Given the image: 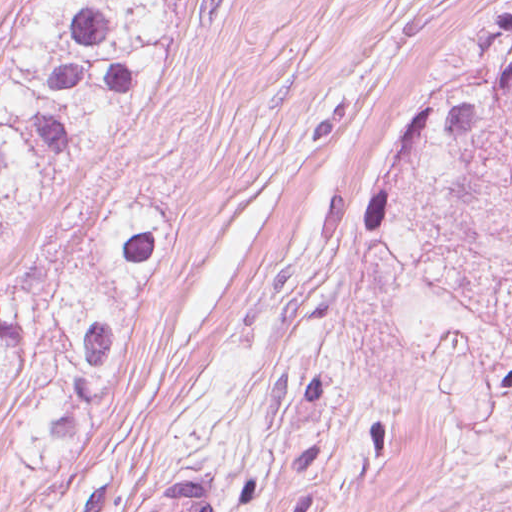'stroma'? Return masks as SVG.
Masks as SVG:
<instances>
[{
  "mask_svg": "<svg viewBox=\"0 0 512 512\" xmlns=\"http://www.w3.org/2000/svg\"><path fill=\"white\" fill-rule=\"evenodd\" d=\"M28 0H0V49ZM436 82L187 2L148 105L0 248L103 192L179 209L105 425L0 512H512V116L459 128L368 233Z\"/></svg>",
  "mask_w": 512,
  "mask_h": 512,
  "instance_id": "1",
  "label": "stroma"
}]
</instances>
